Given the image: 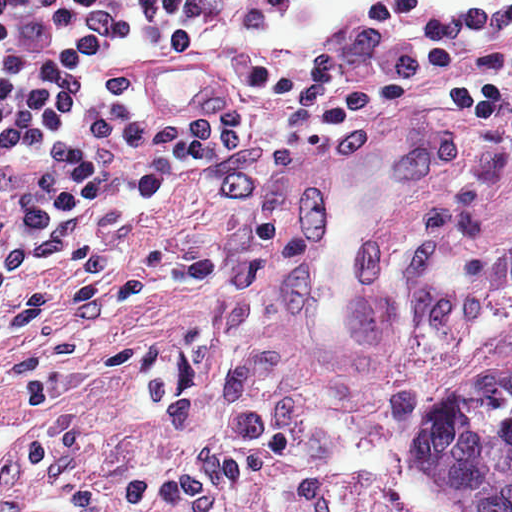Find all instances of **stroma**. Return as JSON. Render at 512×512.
Masks as SVG:
<instances>
[{"instance_id":"stroma-1","label":"stroma","mask_w":512,"mask_h":512,"mask_svg":"<svg viewBox=\"0 0 512 512\" xmlns=\"http://www.w3.org/2000/svg\"><path fill=\"white\" fill-rule=\"evenodd\" d=\"M359 1L282 4L276 48ZM507 364L511 130L325 134L256 251L231 185L169 178L0 310V512H452L425 409Z\"/></svg>"}]
</instances>
